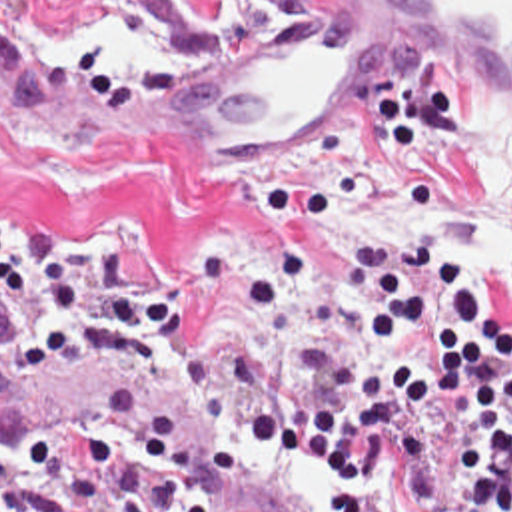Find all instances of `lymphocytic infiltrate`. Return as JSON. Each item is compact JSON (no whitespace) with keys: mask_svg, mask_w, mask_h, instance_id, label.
I'll use <instances>...</instances> for the list:
<instances>
[{"mask_svg":"<svg viewBox=\"0 0 512 512\" xmlns=\"http://www.w3.org/2000/svg\"><path fill=\"white\" fill-rule=\"evenodd\" d=\"M352 267L382 305L370 347L314 335L300 367L332 394L260 400L242 430L328 482L380 476L394 444L416 512H512V323L491 319L471 269L423 241L372 245ZM0 301L36 307L20 371L150 373L180 341V299L162 275L106 243L4 219ZM0 512L120 510L110 486L50 470L22 444L0 452Z\"/></svg>","mask_w":512,"mask_h":512,"instance_id":"f902f5d3","label":"lymphocytic infiltrate"}]
</instances>
